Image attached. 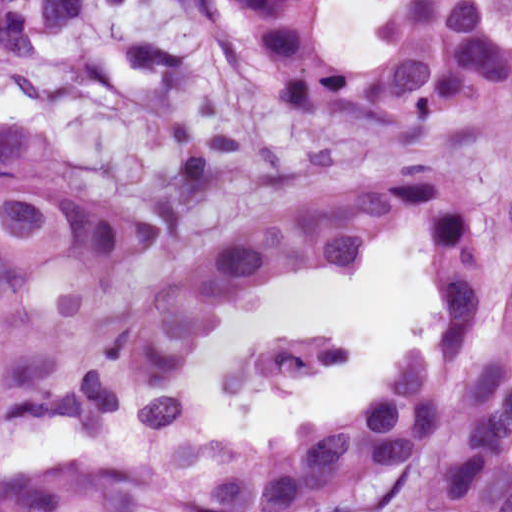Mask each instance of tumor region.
<instances>
[{
    "label": "tumor region",
    "instance_id": "obj_1",
    "mask_svg": "<svg viewBox=\"0 0 512 512\" xmlns=\"http://www.w3.org/2000/svg\"><path fill=\"white\" fill-rule=\"evenodd\" d=\"M254 74L324 125L406 134L452 129L512 103V0H397L380 53L352 67L317 28L313 0H220ZM101 0H0V62L93 23ZM175 219L71 197L44 143L0 128V321L76 316L140 279ZM404 239L427 258L434 322L378 401L318 419L310 443L345 498L512 424V284L501 332L473 334L495 280L475 199L437 171L359 182L207 247L104 339L29 342L0 356V440L116 406L171 421V387L202 337L251 296L307 272L340 277ZM338 353L237 386H289Z\"/></svg>",
    "mask_w": 512,
    "mask_h": 512
}]
</instances>
